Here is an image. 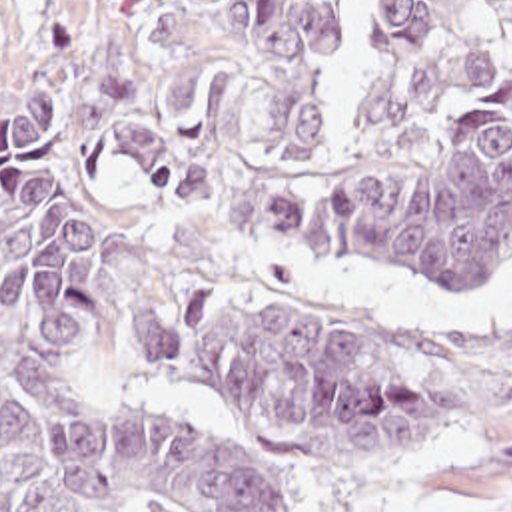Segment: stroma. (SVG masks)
<instances>
[{
    "label": "stroma",
    "instance_id": "obj_1",
    "mask_svg": "<svg viewBox=\"0 0 512 512\" xmlns=\"http://www.w3.org/2000/svg\"><path fill=\"white\" fill-rule=\"evenodd\" d=\"M140 0H0V110L32 78L68 88L66 122L36 154L72 180L102 230L106 288L58 408L80 422L176 416L226 436L280 487L292 512H512V354L473 372L477 420L437 446L363 466H292L240 412L184 398L148 374L144 344L176 294L252 282L375 336L463 340L512 324V256L457 280H425L337 244L252 230L196 212L126 162L112 126L108 72ZM124 512H194L144 489Z\"/></svg>",
    "mask_w": 512,
    "mask_h": 512
}]
</instances>
